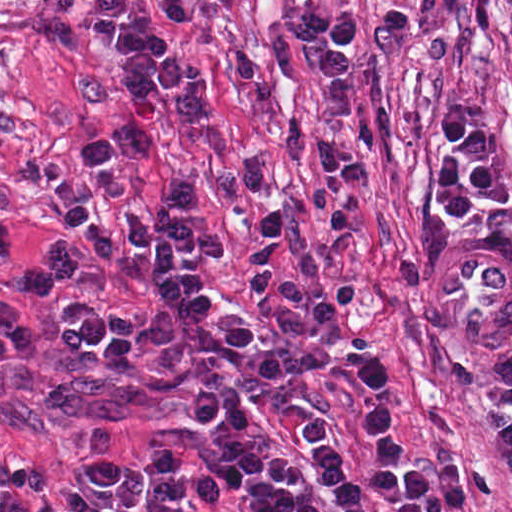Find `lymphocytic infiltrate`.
<instances>
[{"label": "lymphocytic infiltrate", "instance_id": "lymphocytic-infiltrate-1", "mask_svg": "<svg viewBox=\"0 0 512 512\" xmlns=\"http://www.w3.org/2000/svg\"><path fill=\"white\" fill-rule=\"evenodd\" d=\"M168 17L184 22L194 16L198 0H163ZM233 15L243 0H207ZM491 0H465L469 27H485ZM287 30L310 45L301 57L305 68L320 77L328 91L324 117L317 130V158L325 188L351 193L364 181V163L341 141V127L351 106L350 60L358 47L362 20L330 15L312 8H295ZM82 34L89 46L106 45L117 63V76L126 96L119 126L89 136L81 143L70 173L57 179L47 194L49 208L81 231L94 216L98 182L110 163L137 161L152 142L146 117L149 109L176 126L189 127L206 118L211 99L198 65L184 52L176 35L141 0H93L83 15ZM292 237L282 207H262L256 239L249 256L251 294L260 317L292 335H311L351 304V285L334 281L309 293L292 282L284 251ZM142 467L149 473L144 486L145 509L179 512L197 503L204 512H229L213 476L187 466L169 450L148 454ZM467 499V473L461 464H442L413 483L412 512H461Z\"/></svg>", "mask_w": 512, "mask_h": 512}]
</instances>
